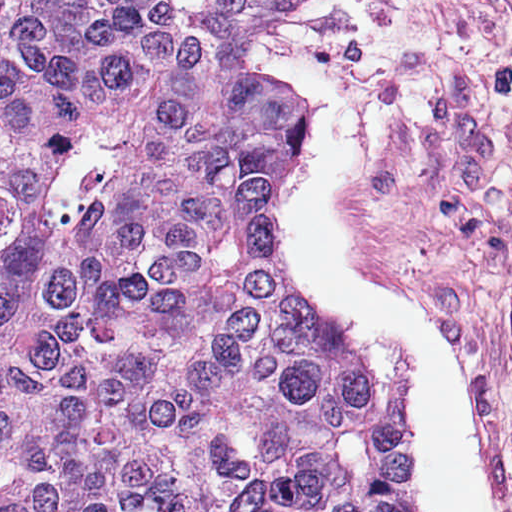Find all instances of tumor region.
Returning a JSON list of instances; mask_svg holds the SVG:
<instances>
[{"label": "tumor region", "instance_id": "e687c5a6", "mask_svg": "<svg viewBox=\"0 0 512 512\" xmlns=\"http://www.w3.org/2000/svg\"><path fill=\"white\" fill-rule=\"evenodd\" d=\"M279 1L0 0V512H409L274 239Z\"/></svg>", "mask_w": 512, "mask_h": 512}]
</instances>
